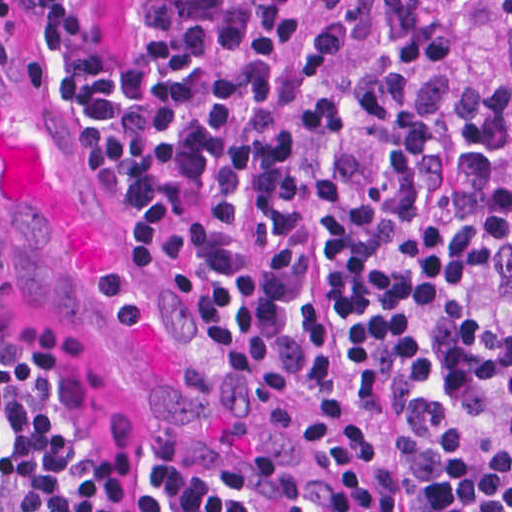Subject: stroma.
I'll list each match as a JSON object with an SVG mask.
<instances>
[{
	"label": "stroma",
	"instance_id": "stroma-1",
	"mask_svg": "<svg viewBox=\"0 0 512 512\" xmlns=\"http://www.w3.org/2000/svg\"><path fill=\"white\" fill-rule=\"evenodd\" d=\"M437 1L450 15L457 77L472 84L505 81L512 90V8L503 0ZM12 2L10 23H0V60L14 68L1 62L0 66L30 97L48 130L62 140L100 194L104 139L78 111L57 56L54 33L24 0ZM93 19L104 46L126 65L131 0H96ZM499 282L512 311V245L505 248L499 263ZM0 319L29 345L49 349L66 366L114 459L133 470L174 468L153 447L110 376L80 342L23 309L1 285ZM307 460L330 484L321 464Z\"/></svg>",
	"mask_w": 512,
	"mask_h": 512
}]
</instances>
